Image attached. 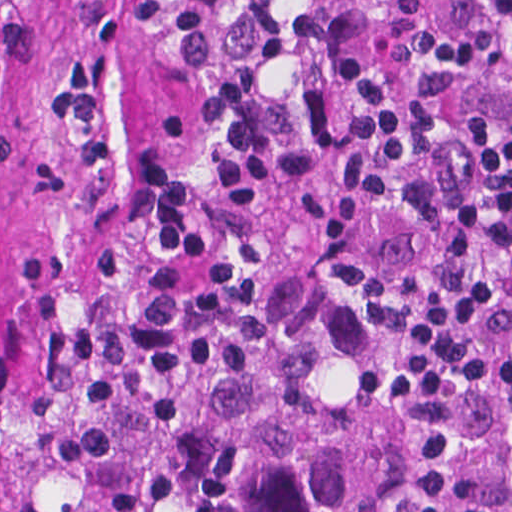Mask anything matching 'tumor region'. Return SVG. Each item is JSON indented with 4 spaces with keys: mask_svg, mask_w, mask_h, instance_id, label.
I'll return each mask as SVG.
<instances>
[{
    "mask_svg": "<svg viewBox=\"0 0 512 512\" xmlns=\"http://www.w3.org/2000/svg\"><path fill=\"white\" fill-rule=\"evenodd\" d=\"M384 0H0V512H512V425L364 384L309 205Z\"/></svg>",
    "mask_w": 512,
    "mask_h": 512,
    "instance_id": "1",
    "label": "tumor region"
}]
</instances>
